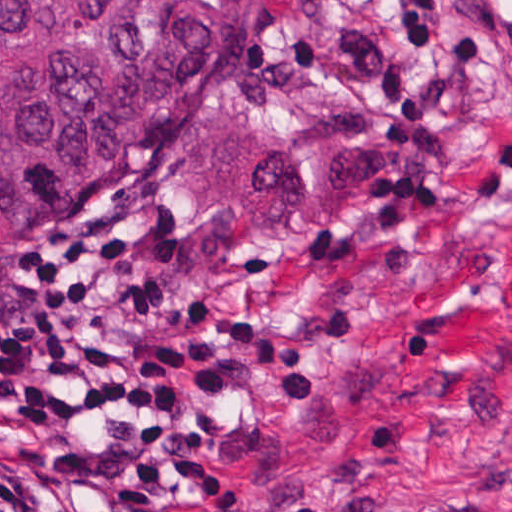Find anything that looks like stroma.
I'll use <instances>...</instances> for the list:
<instances>
[{"label": "stroma", "instance_id": "1", "mask_svg": "<svg viewBox=\"0 0 512 512\" xmlns=\"http://www.w3.org/2000/svg\"><path fill=\"white\" fill-rule=\"evenodd\" d=\"M445 19L486 23L490 49L459 62L423 147L396 151L382 76L404 20L369 0H250L171 132L20 254L64 230L133 250L161 201L190 297L311 345L310 401L235 383L241 512H512V188L475 192L512 114V0H445ZM159 512L199 511L166 485Z\"/></svg>", "mask_w": 512, "mask_h": 512}]
</instances>
